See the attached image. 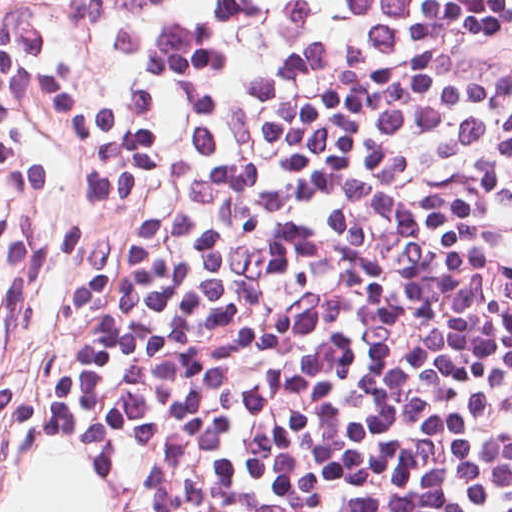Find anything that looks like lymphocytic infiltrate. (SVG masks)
I'll return each instance as SVG.
<instances>
[{
    "label": "lymphocytic infiltrate",
    "instance_id": "1",
    "mask_svg": "<svg viewBox=\"0 0 512 512\" xmlns=\"http://www.w3.org/2000/svg\"><path fill=\"white\" fill-rule=\"evenodd\" d=\"M0 172L132 512H512V0H0Z\"/></svg>",
    "mask_w": 512,
    "mask_h": 512
}]
</instances>
